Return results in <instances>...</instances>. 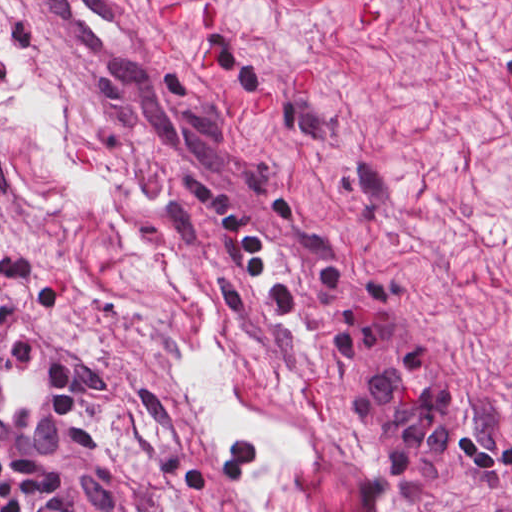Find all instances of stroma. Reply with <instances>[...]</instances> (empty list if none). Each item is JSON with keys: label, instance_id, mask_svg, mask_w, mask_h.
<instances>
[{"label": "stroma", "instance_id": "stroma-1", "mask_svg": "<svg viewBox=\"0 0 512 512\" xmlns=\"http://www.w3.org/2000/svg\"><path fill=\"white\" fill-rule=\"evenodd\" d=\"M201 1L211 30L200 0H0V115L53 96L114 192L0 116V272L52 308L118 484L139 512H512V0ZM188 286L277 437L225 447L177 373L213 323Z\"/></svg>", "mask_w": 512, "mask_h": 512}]
</instances>
